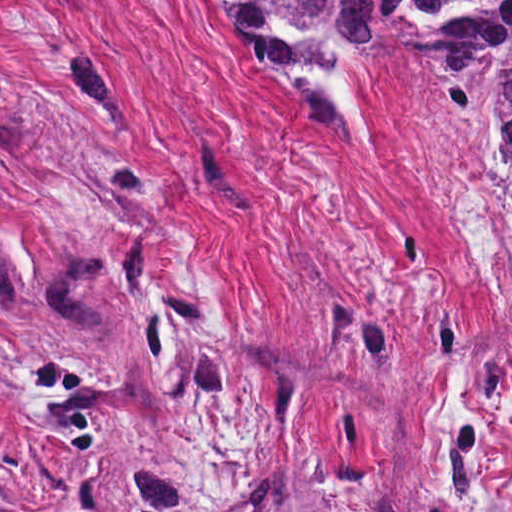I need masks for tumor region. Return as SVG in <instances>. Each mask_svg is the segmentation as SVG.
Wrapping results in <instances>:
<instances>
[{"label":"tumor region","mask_w":512,"mask_h":512,"mask_svg":"<svg viewBox=\"0 0 512 512\" xmlns=\"http://www.w3.org/2000/svg\"><path fill=\"white\" fill-rule=\"evenodd\" d=\"M234 44L254 65L288 75L317 66L279 33L288 28L318 61L335 66L321 40H388L410 14L434 48V86L463 121L512 126V0H206Z\"/></svg>","instance_id":"obj_1"}]
</instances>
